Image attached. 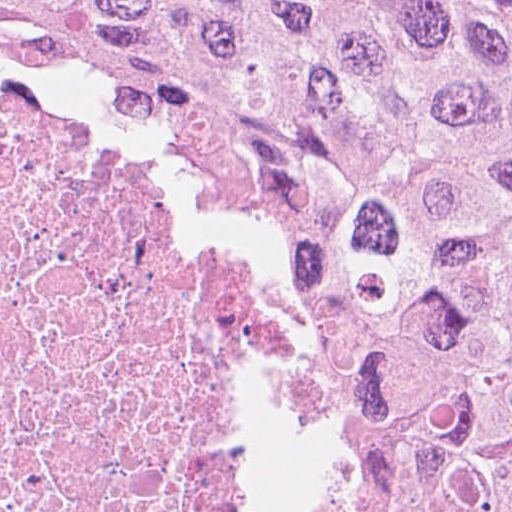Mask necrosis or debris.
<instances>
[{
    "label": "necrosis or debris",
    "mask_w": 512,
    "mask_h": 512,
    "mask_svg": "<svg viewBox=\"0 0 512 512\" xmlns=\"http://www.w3.org/2000/svg\"><path fill=\"white\" fill-rule=\"evenodd\" d=\"M273 417L219 245L0 89V512H256Z\"/></svg>",
    "instance_id": "necrosis-or-debris-1"
}]
</instances>
